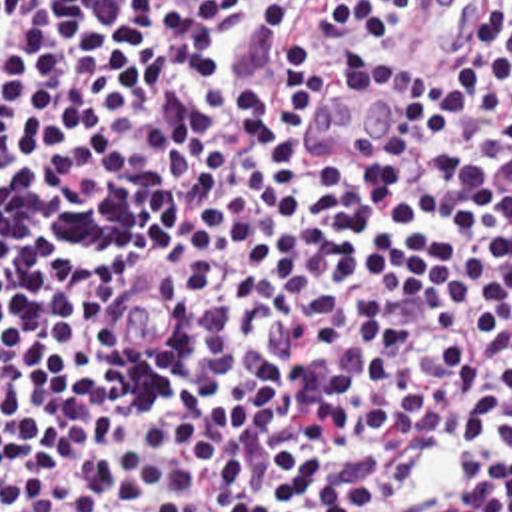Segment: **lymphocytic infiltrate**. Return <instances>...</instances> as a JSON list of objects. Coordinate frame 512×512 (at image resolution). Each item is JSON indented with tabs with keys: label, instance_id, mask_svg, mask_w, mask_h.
<instances>
[{
	"label": "lymphocytic infiltrate",
	"instance_id": "1",
	"mask_svg": "<svg viewBox=\"0 0 512 512\" xmlns=\"http://www.w3.org/2000/svg\"><path fill=\"white\" fill-rule=\"evenodd\" d=\"M433 3L0 0V512H512V0L304 133Z\"/></svg>",
	"mask_w": 512,
	"mask_h": 512
}]
</instances>
